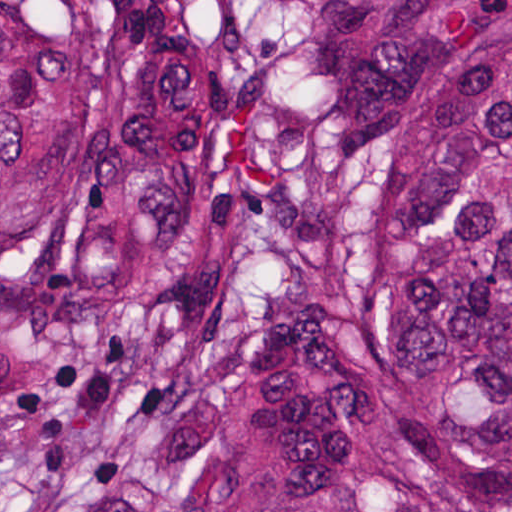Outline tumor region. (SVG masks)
<instances>
[{
  "instance_id": "tumor-region-1",
  "label": "tumor region",
  "mask_w": 512,
  "mask_h": 512,
  "mask_svg": "<svg viewBox=\"0 0 512 512\" xmlns=\"http://www.w3.org/2000/svg\"><path fill=\"white\" fill-rule=\"evenodd\" d=\"M0 512H512V0H0Z\"/></svg>"
}]
</instances>
